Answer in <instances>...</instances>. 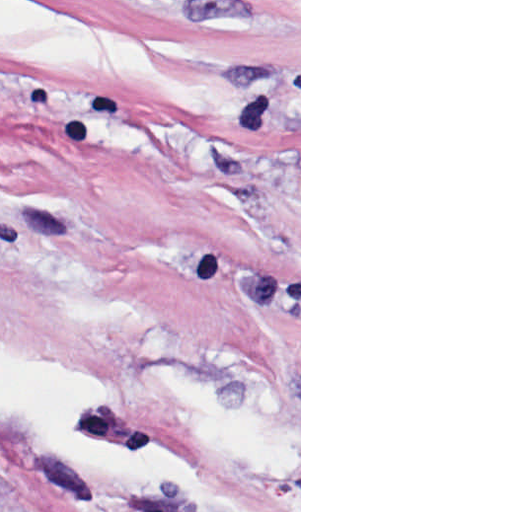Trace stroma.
I'll return each mask as SVG.
<instances>
[{"mask_svg":"<svg viewBox=\"0 0 512 512\" xmlns=\"http://www.w3.org/2000/svg\"><path fill=\"white\" fill-rule=\"evenodd\" d=\"M0 512H301V0H0Z\"/></svg>","mask_w":512,"mask_h":512,"instance_id":"1","label":"stroma"}]
</instances>
